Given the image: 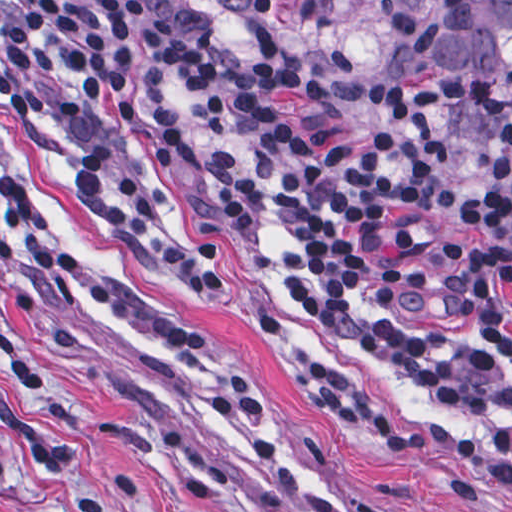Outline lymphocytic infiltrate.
Masks as SVG:
<instances>
[{
	"instance_id": "lymphocytic-infiltrate-1",
	"label": "lymphocytic infiltrate",
	"mask_w": 512,
	"mask_h": 512,
	"mask_svg": "<svg viewBox=\"0 0 512 512\" xmlns=\"http://www.w3.org/2000/svg\"><path fill=\"white\" fill-rule=\"evenodd\" d=\"M179 95L191 99L204 158L200 221L256 265L265 231L280 228L285 289L337 325L432 299L428 247L451 206L452 164L471 160L477 184L460 202L470 239L441 243L432 264L445 311L473 313L491 337L512 344V143L463 128L449 89H388L376 118L349 128L294 90L193 49L137 0H0V109L51 136L89 224L164 285L208 302L228 288L220 248L147 210L132 159L139 119L154 169L179 166L168 112ZM31 281L69 293L124 345L200 366L190 402L204 440L295 492L274 404L220 331L171 319L116 288L66 247L52 210L0 167V308ZM257 325L280 375L371 450L456 456L512 496V443L450 432L308 348L291 327ZM365 345L382 367L465 419L512 417V364L483 347L410 321L373 324Z\"/></svg>"
}]
</instances>
